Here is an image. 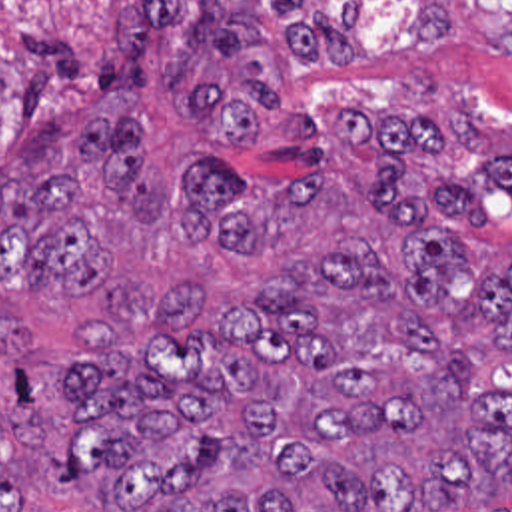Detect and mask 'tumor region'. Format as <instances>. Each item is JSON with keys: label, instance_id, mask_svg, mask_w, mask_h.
<instances>
[{"label": "tumor region", "instance_id": "tumor-region-1", "mask_svg": "<svg viewBox=\"0 0 512 512\" xmlns=\"http://www.w3.org/2000/svg\"><path fill=\"white\" fill-rule=\"evenodd\" d=\"M446 2L416 0L418 50L450 40ZM466 2L512 54V6ZM171 26L169 0L123 10L127 64L103 58L105 90L145 92L147 48ZM285 36L295 60H353L355 6L291 20ZM261 40L251 20L201 0L165 68L167 90L193 88L189 114L221 148H255L279 90L251 60L233 96L195 84L211 54L233 58ZM339 124L366 152L374 212L400 224L398 258L339 236L205 326L209 286L111 292L69 360L19 374L0 406V512L25 511L27 447L43 453L47 489L109 495L99 512H434L512 485V260L498 274L470 246L496 194L512 192V154L416 184L402 160L442 156L436 124L361 104H345ZM143 156L131 116H101L73 142L79 166L123 190L133 224H163L165 174ZM207 158L181 170L179 246H277L317 192L315 176ZM41 282L75 298L97 290L93 192L75 172H0V372L29 344L27 324L9 316L13 298Z\"/></svg>", "mask_w": 512, "mask_h": 512}]
</instances>
